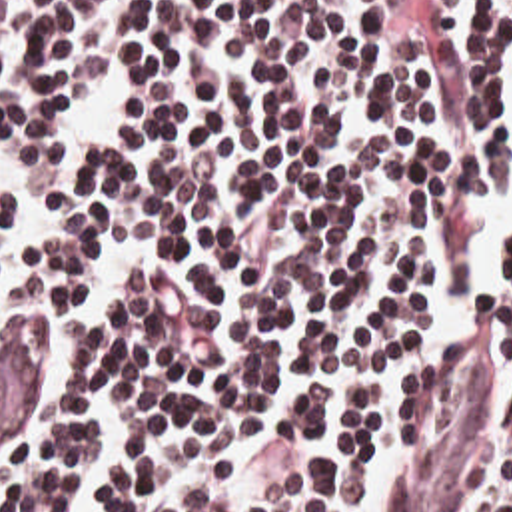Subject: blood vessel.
<instances>
[{
	"mask_svg": "<svg viewBox=\"0 0 512 512\" xmlns=\"http://www.w3.org/2000/svg\"><path fill=\"white\" fill-rule=\"evenodd\" d=\"M475 336L421 370L367 477L363 512H469L475 505L491 466V368L471 346ZM46 366L48 334L38 324L0 330V454H18Z\"/></svg>",
	"mask_w": 512,
	"mask_h": 512,
	"instance_id": "obj_1",
	"label": "blood vessel"
}]
</instances>
